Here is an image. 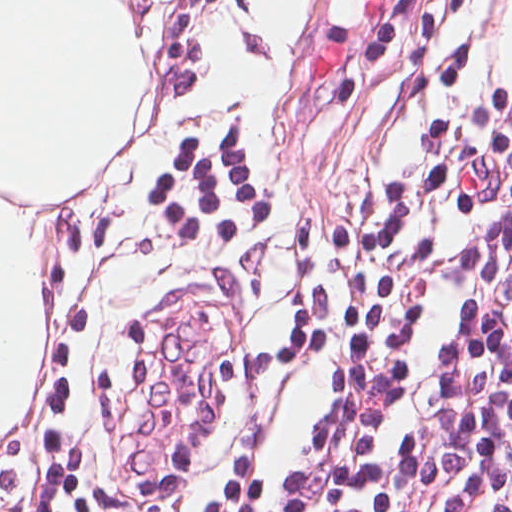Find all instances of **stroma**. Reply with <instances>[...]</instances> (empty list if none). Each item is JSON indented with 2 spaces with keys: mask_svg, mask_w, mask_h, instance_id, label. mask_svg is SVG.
Listing matches in <instances>:
<instances>
[{
  "mask_svg": "<svg viewBox=\"0 0 512 512\" xmlns=\"http://www.w3.org/2000/svg\"><path fill=\"white\" fill-rule=\"evenodd\" d=\"M512 0H298L268 45L168 512H233L292 444L340 261L406 171L512 135L495 57ZM346 42L332 85L303 64Z\"/></svg>",
  "mask_w": 512,
  "mask_h": 512,
  "instance_id": "35a3bbf8",
  "label": "stroma"
}]
</instances>
